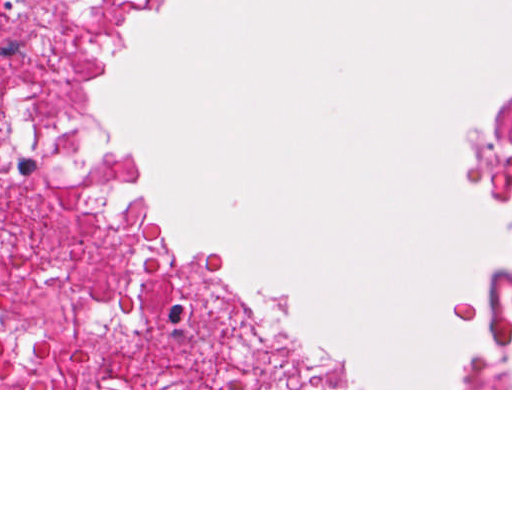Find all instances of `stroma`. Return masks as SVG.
<instances>
[{
	"instance_id": "obj_1",
	"label": "stroma",
	"mask_w": 512,
	"mask_h": 512,
	"mask_svg": "<svg viewBox=\"0 0 512 512\" xmlns=\"http://www.w3.org/2000/svg\"><path fill=\"white\" fill-rule=\"evenodd\" d=\"M95 29V97L118 85L134 55L137 35H160L168 24L151 0H89ZM512 91L470 112L460 142L463 179L491 215H507V192L481 173L474 139L507 107ZM89 150L128 207L142 255L175 327L233 355L272 385L268 388H0V390H512L467 388L480 337L497 310L507 247L481 268L473 297L460 309L476 334L454 361L450 388H374L337 379L320 369L293 332L271 317L262 300L236 278L227 261L180 247L167 233L126 148L124 134L95 116Z\"/></svg>"
}]
</instances>
